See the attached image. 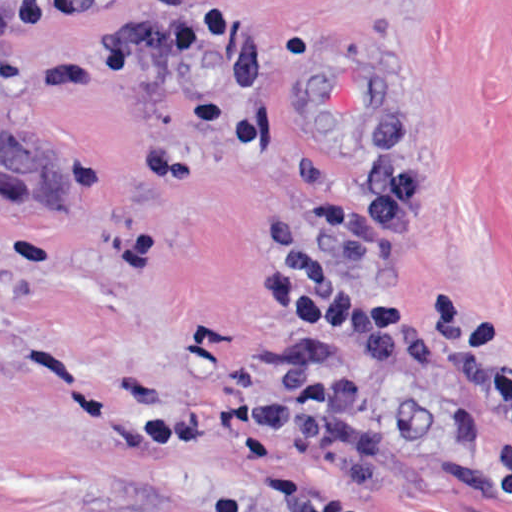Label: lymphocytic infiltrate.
Wrapping results in <instances>:
<instances>
[{
	"mask_svg": "<svg viewBox=\"0 0 512 512\" xmlns=\"http://www.w3.org/2000/svg\"><path fill=\"white\" fill-rule=\"evenodd\" d=\"M370 158L357 191H330L302 212L286 261L260 263L257 283L288 328L289 351L254 374L249 394L205 396L143 417L144 457L187 460L249 441L279 442L351 474L379 439V401L339 341L386 373L420 371L501 422L512 441V322L433 292L414 307L393 288V263L418 227V181L399 144L391 84H356Z\"/></svg>",
	"mask_w": 512,
	"mask_h": 512,
	"instance_id": "obj_1",
	"label": "lymphocytic infiltrate"
}]
</instances>
